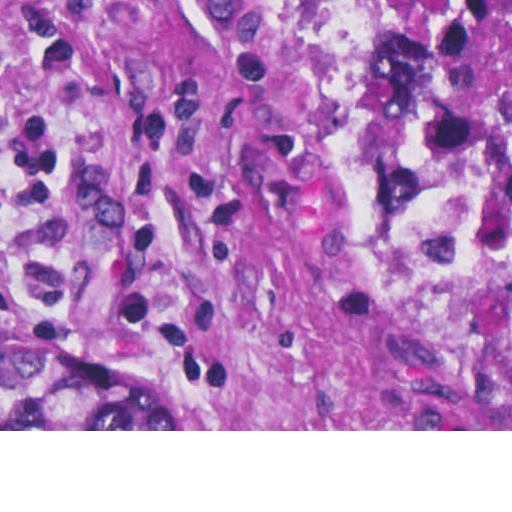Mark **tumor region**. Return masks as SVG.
<instances>
[{
  "label": "tumor region",
  "mask_w": 512,
  "mask_h": 512,
  "mask_svg": "<svg viewBox=\"0 0 512 512\" xmlns=\"http://www.w3.org/2000/svg\"><path fill=\"white\" fill-rule=\"evenodd\" d=\"M294 142L370 311L461 429H512V0H258ZM1 429H183L157 371L1 339Z\"/></svg>",
  "instance_id": "1"
}]
</instances>
